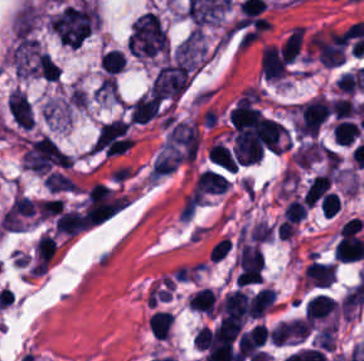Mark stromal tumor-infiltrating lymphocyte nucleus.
<instances>
[{"label":"stromal tumor-infiltrating lymphocyte nucleus","instance_id":"obj_11","mask_svg":"<svg viewBox=\"0 0 364 361\" xmlns=\"http://www.w3.org/2000/svg\"><path fill=\"white\" fill-rule=\"evenodd\" d=\"M330 185V173L327 172L313 176L309 181L303 196L306 201L313 206L324 196Z\"/></svg>","mask_w":364,"mask_h":361},{"label":"stromal tumor-infiltrating lymphocyte nucleus","instance_id":"obj_6","mask_svg":"<svg viewBox=\"0 0 364 361\" xmlns=\"http://www.w3.org/2000/svg\"><path fill=\"white\" fill-rule=\"evenodd\" d=\"M229 185L225 174L220 172L204 169L198 176L193 189L197 193H217L222 192Z\"/></svg>","mask_w":364,"mask_h":361},{"label":"stromal tumor-infiltrating lymphocyte nucleus","instance_id":"obj_12","mask_svg":"<svg viewBox=\"0 0 364 361\" xmlns=\"http://www.w3.org/2000/svg\"><path fill=\"white\" fill-rule=\"evenodd\" d=\"M355 120L341 118L332 128V139L340 145H348L359 135Z\"/></svg>","mask_w":364,"mask_h":361},{"label":"stromal tumor-infiltrating lymphocyte nucleus","instance_id":"obj_13","mask_svg":"<svg viewBox=\"0 0 364 361\" xmlns=\"http://www.w3.org/2000/svg\"><path fill=\"white\" fill-rule=\"evenodd\" d=\"M173 320V316L168 311H154L148 318V329L158 338H167Z\"/></svg>","mask_w":364,"mask_h":361},{"label":"stromal tumor-infiltrating lymphocyte nucleus","instance_id":"obj_17","mask_svg":"<svg viewBox=\"0 0 364 361\" xmlns=\"http://www.w3.org/2000/svg\"><path fill=\"white\" fill-rule=\"evenodd\" d=\"M307 211V203L301 198L294 197L287 203L283 211L284 221L299 222L305 217Z\"/></svg>","mask_w":364,"mask_h":361},{"label":"stromal tumor-infiltrating lymphocyte nucleus","instance_id":"obj_1","mask_svg":"<svg viewBox=\"0 0 364 361\" xmlns=\"http://www.w3.org/2000/svg\"><path fill=\"white\" fill-rule=\"evenodd\" d=\"M34 212V203L28 197L15 196L6 209L0 225L5 230H22Z\"/></svg>","mask_w":364,"mask_h":361},{"label":"stromal tumor-infiltrating lymphocyte nucleus","instance_id":"obj_15","mask_svg":"<svg viewBox=\"0 0 364 361\" xmlns=\"http://www.w3.org/2000/svg\"><path fill=\"white\" fill-rule=\"evenodd\" d=\"M304 27L302 25H294L289 32L284 46L282 48V54L287 62H293L298 54Z\"/></svg>","mask_w":364,"mask_h":361},{"label":"stromal tumor-infiltrating lymphocyte nucleus","instance_id":"obj_10","mask_svg":"<svg viewBox=\"0 0 364 361\" xmlns=\"http://www.w3.org/2000/svg\"><path fill=\"white\" fill-rule=\"evenodd\" d=\"M275 301V291L262 287L249 299L248 314L252 317H263Z\"/></svg>","mask_w":364,"mask_h":361},{"label":"stromal tumor-infiltrating lymphocyte nucleus","instance_id":"obj_3","mask_svg":"<svg viewBox=\"0 0 364 361\" xmlns=\"http://www.w3.org/2000/svg\"><path fill=\"white\" fill-rule=\"evenodd\" d=\"M336 274V267L330 261L310 260L306 266L303 283L306 286L327 287Z\"/></svg>","mask_w":364,"mask_h":361},{"label":"stromal tumor-infiltrating lymphocyte nucleus","instance_id":"obj_14","mask_svg":"<svg viewBox=\"0 0 364 361\" xmlns=\"http://www.w3.org/2000/svg\"><path fill=\"white\" fill-rule=\"evenodd\" d=\"M209 158L224 168L236 170L239 165L228 147L218 140L209 149Z\"/></svg>","mask_w":364,"mask_h":361},{"label":"stromal tumor-infiltrating lymphocyte nucleus","instance_id":"obj_8","mask_svg":"<svg viewBox=\"0 0 364 361\" xmlns=\"http://www.w3.org/2000/svg\"><path fill=\"white\" fill-rule=\"evenodd\" d=\"M58 233L75 236L81 231L88 228L81 211L75 208L62 214L55 222Z\"/></svg>","mask_w":364,"mask_h":361},{"label":"stromal tumor-infiltrating lymphocyte nucleus","instance_id":"obj_9","mask_svg":"<svg viewBox=\"0 0 364 361\" xmlns=\"http://www.w3.org/2000/svg\"><path fill=\"white\" fill-rule=\"evenodd\" d=\"M188 305L193 308L207 313H215L217 310L216 291L202 286L193 291L188 298Z\"/></svg>","mask_w":364,"mask_h":361},{"label":"stromal tumor-infiltrating lymphocyte nucleus","instance_id":"obj_5","mask_svg":"<svg viewBox=\"0 0 364 361\" xmlns=\"http://www.w3.org/2000/svg\"><path fill=\"white\" fill-rule=\"evenodd\" d=\"M364 255L363 240L351 231H341L335 248V257L344 262L355 261Z\"/></svg>","mask_w":364,"mask_h":361},{"label":"stromal tumor-infiltrating lymphocyte nucleus","instance_id":"obj_2","mask_svg":"<svg viewBox=\"0 0 364 361\" xmlns=\"http://www.w3.org/2000/svg\"><path fill=\"white\" fill-rule=\"evenodd\" d=\"M250 297L244 289H234L224 295L220 302V313L223 319L245 321Z\"/></svg>","mask_w":364,"mask_h":361},{"label":"stromal tumor-infiltrating lymphocyte nucleus","instance_id":"obj_7","mask_svg":"<svg viewBox=\"0 0 364 361\" xmlns=\"http://www.w3.org/2000/svg\"><path fill=\"white\" fill-rule=\"evenodd\" d=\"M336 310L337 302L335 300L317 293L305 302L303 314L314 321L328 316Z\"/></svg>","mask_w":364,"mask_h":361},{"label":"stromal tumor-infiltrating lymphocyte nucleus","instance_id":"obj_19","mask_svg":"<svg viewBox=\"0 0 364 361\" xmlns=\"http://www.w3.org/2000/svg\"><path fill=\"white\" fill-rule=\"evenodd\" d=\"M340 199L336 192L329 191L322 199L320 208L326 216H333L340 206Z\"/></svg>","mask_w":364,"mask_h":361},{"label":"stromal tumor-infiltrating lymphocyte nucleus","instance_id":"obj_16","mask_svg":"<svg viewBox=\"0 0 364 361\" xmlns=\"http://www.w3.org/2000/svg\"><path fill=\"white\" fill-rule=\"evenodd\" d=\"M103 71L106 73H117L123 71L126 58L117 49H111L101 54L100 57Z\"/></svg>","mask_w":364,"mask_h":361},{"label":"stromal tumor-infiltrating lymphocyte nucleus","instance_id":"obj_18","mask_svg":"<svg viewBox=\"0 0 364 361\" xmlns=\"http://www.w3.org/2000/svg\"><path fill=\"white\" fill-rule=\"evenodd\" d=\"M331 111L335 117L343 118L357 111L356 104L348 96L332 99Z\"/></svg>","mask_w":364,"mask_h":361},{"label":"stromal tumor-infiltrating lymphocyte nucleus","instance_id":"obj_4","mask_svg":"<svg viewBox=\"0 0 364 361\" xmlns=\"http://www.w3.org/2000/svg\"><path fill=\"white\" fill-rule=\"evenodd\" d=\"M260 71L265 79H278L284 77L287 63L278 47L267 45L263 49Z\"/></svg>","mask_w":364,"mask_h":361}]
</instances>
